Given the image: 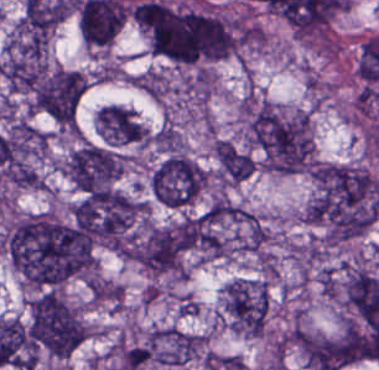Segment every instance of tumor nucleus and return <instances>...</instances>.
I'll use <instances>...</instances> for the list:
<instances>
[{
  "mask_svg": "<svg viewBox=\"0 0 379 370\" xmlns=\"http://www.w3.org/2000/svg\"><path fill=\"white\" fill-rule=\"evenodd\" d=\"M240 115L245 139L266 171H310L313 139L307 109L263 97H244Z\"/></svg>",
  "mask_w": 379,
  "mask_h": 370,
  "instance_id": "obj_4",
  "label": "tumor nucleus"
},
{
  "mask_svg": "<svg viewBox=\"0 0 379 370\" xmlns=\"http://www.w3.org/2000/svg\"><path fill=\"white\" fill-rule=\"evenodd\" d=\"M28 332L37 352L66 358L87 336V325L69 299L49 289L30 301Z\"/></svg>",
  "mask_w": 379,
  "mask_h": 370,
  "instance_id": "obj_5",
  "label": "tumor nucleus"
},
{
  "mask_svg": "<svg viewBox=\"0 0 379 370\" xmlns=\"http://www.w3.org/2000/svg\"><path fill=\"white\" fill-rule=\"evenodd\" d=\"M96 132L108 145L144 144L148 131L132 109L105 103L95 114Z\"/></svg>",
  "mask_w": 379,
  "mask_h": 370,
  "instance_id": "obj_12",
  "label": "tumor nucleus"
},
{
  "mask_svg": "<svg viewBox=\"0 0 379 370\" xmlns=\"http://www.w3.org/2000/svg\"><path fill=\"white\" fill-rule=\"evenodd\" d=\"M135 21L151 51L177 64L230 57L241 37V20L224 12L154 0L138 5Z\"/></svg>",
  "mask_w": 379,
  "mask_h": 370,
  "instance_id": "obj_1",
  "label": "tumor nucleus"
},
{
  "mask_svg": "<svg viewBox=\"0 0 379 370\" xmlns=\"http://www.w3.org/2000/svg\"><path fill=\"white\" fill-rule=\"evenodd\" d=\"M126 255L146 274H184L185 249L179 219L147 223L133 237Z\"/></svg>",
  "mask_w": 379,
  "mask_h": 370,
  "instance_id": "obj_7",
  "label": "tumor nucleus"
},
{
  "mask_svg": "<svg viewBox=\"0 0 379 370\" xmlns=\"http://www.w3.org/2000/svg\"><path fill=\"white\" fill-rule=\"evenodd\" d=\"M207 174L203 167L183 151H169L148 177L154 200L163 206L184 208L200 194Z\"/></svg>",
  "mask_w": 379,
  "mask_h": 370,
  "instance_id": "obj_9",
  "label": "tumor nucleus"
},
{
  "mask_svg": "<svg viewBox=\"0 0 379 370\" xmlns=\"http://www.w3.org/2000/svg\"><path fill=\"white\" fill-rule=\"evenodd\" d=\"M379 213V180L359 165L314 164L303 214L323 243L369 228Z\"/></svg>",
  "mask_w": 379,
  "mask_h": 370,
  "instance_id": "obj_3",
  "label": "tumor nucleus"
},
{
  "mask_svg": "<svg viewBox=\"0 0 379 370\" xmlns=\"http://www.w3.org/2000/svg\"><path fill=\"white\" fill-rule=\"evenodd\" d=\"M152 141L159 150H185V140L180 130L171 122H164L154 133Z\"/></svg>",
  "mask_w": 379,
  "mask_h": 370,
  "instance_id": "obj_14",
  "label": "tumor nucleus"
},
{
  "mask_svg": "<svg viewBox=\"0 0 379 370\" xmlns=\"http://www.w3.org/2000/svg\"><path fill=\"white\" fill-rule=\"evenodd\" d=\"M8 262L29 289H48L85 273L83 229L50 212L22 215L1 240Z\"/></svg>",
  "mask_w": 379,
  "mask_h": 370,
  "instance_id": "obj_2",
  "label": "tumor nucleus"
},
{
  "mask_svg": "<svg viewBox=\"0 0 379 370\" xmlns=\"http://www.w3.org/2000/svg\"><path fill=\"white\" fill-rule=\"evenodd\" d=\"M269 314V289L264 279L235 278L223 290L221 316L236 333L263 336Z\"/></svg>",
  "mask_w": 379,
  "mask_h": 370,
  "instance_id": "obj_10",
  "label": "tumor nucleus"
},
{
  "mask_svg": "<svg viewBox=\"0 0 379 370\" xmlns=\"http://www.w3.org/2000/svg\"><path fill=\"white\" fill-rule=\"evenodd\" d=\"M129 156L112 145L81 141L63 160L65 174L75 187L100 192L113 190Z\"/></svg>",
  "mask_w": 379,
  "mask_h": 370,
  "instance_id": "obj_8",
  "label": "tumor nucleus"
},
{
  "mask_svg": "<svg viewBox=\"0 0 379 370\" xmlns=\"http://www.w3.org/2000/svg\"><path fill=\"white\" fill-rule=\"evenodd\" d=\"M87 86L83 72L44 65L29 91V111L61 128L75 129Z\"/></svg>",
  "mask_w": 379,
  "mask_h": 370,
  "instance_id": "obj_6",
  "label": "tumor nucleus"
},
{
  "mask_svg": "<svg viewBox=\"0 0 379 370\" xmlns=\"http://www.w3.org/2000/svg\"><path fill=\"white\" fill-rule=\"evenodd\" d=\"M214 157L218 178L226 183L236 185L250 177L256 170L253 155L225 138H218L215 142Z\"/></svg>",
  "mask_w": 379,
  "mask_h": 370,
  "instance_id": "obj_13",
  "label": "tumor nucleus"
},
{
  "mask_svg": "<svg viewBox=\"0 0 379 370\" xmlns=\"http://www.w3.org/2000/svg\"><path fill=\"white\" fill-rule=\"evenodd\" d=\"M207 336L170 325L154 326L145 336L147 362L185 366L205 356Z\"/></svg>",
  "mask_w": 379,
  "mask_h": 370,
  "instance_id": "obj_11",
  "label": "tumor nucleus"
}]
</instances>
